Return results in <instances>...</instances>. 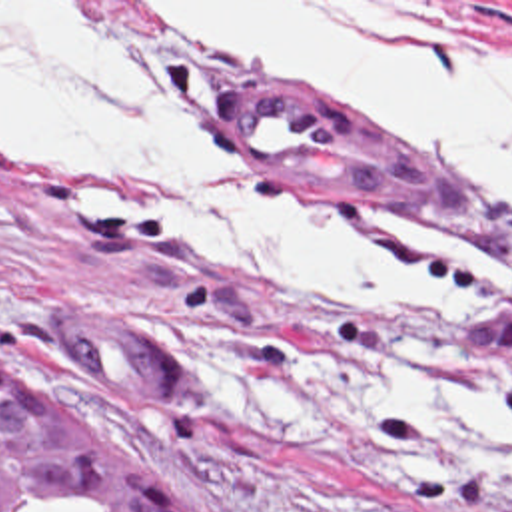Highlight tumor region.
<instances>
[{
    "label": "tumor region",
    "mask_w": 512,
    "mask_h": 512,
    "mask_svg": "<svg viewBox=\"0 0 512 512\" xmlns=\"http://www.w3.org/2000/svg\"><path fill=\"white\" fill-rule=\"evenodd\" d=\"M0 512H205L123 433L0 371Z\"/></svg>",
    "instance_id": "obj_1"
}]
</instances>
